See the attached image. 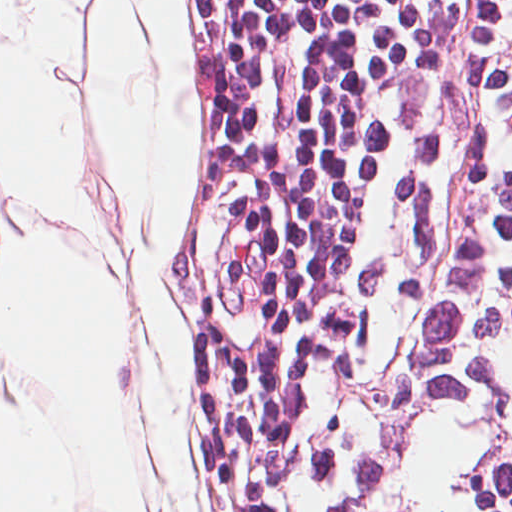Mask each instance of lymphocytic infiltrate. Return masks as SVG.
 I'll list each match as a JSON object with an SVG mask.
<instances>
[{
    "mask_svg": "<svg viewBox=\"0 0 512 512\" xmlns=\"http://www.w3.org/2000/svg\"><path fill=\"white\" fill-rule=\"evenodd\" d=\"M354 512H512V0H462Z\"/></svg>",
    "mask_w": 512,
    "mask_h": 512,
    "instance_id": "1",
    "label": "lymphocytic infiltrate"
}]
</instances>
